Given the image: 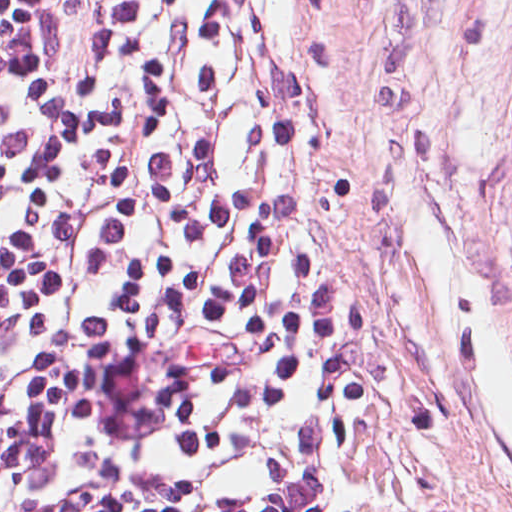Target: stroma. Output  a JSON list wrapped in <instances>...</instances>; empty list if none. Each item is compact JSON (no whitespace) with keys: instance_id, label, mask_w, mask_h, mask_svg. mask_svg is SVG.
Returning <instances> with one entry per match:
<instances>
[{"instance_id":"stroma-1","label":"stroma","mask_w":512,"mask_h":512,"mask_svg":"<svg viewBox=\"0 0 512 512\" xmlns=\"http://www.w3.org/2000/svg\"><path fill=\"white\" fill-rule=\"evenodd\" d=\"M390 512H512V0H311Z\"/></svg>"}]
</instances>
